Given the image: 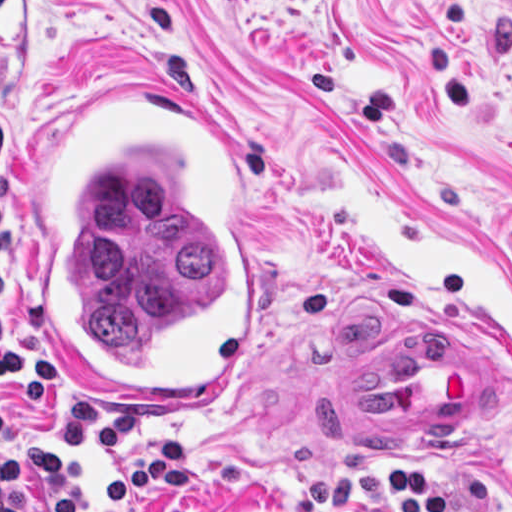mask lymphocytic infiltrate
Wrapping results in <instances>:
<instances>
[{
    "label": "lymphocytic infiltrate",
    "instance_id": "obj_1",
    "mask_svg": "<svg viewBox=\"0 0 512 512\" xmlns=\"http://www.w3.org/2000/svg\"><path fill=\"white\" fill-rule=\"evenodd\" d=\"M17 291V234L0 223V384L16 388L21 411L65 393L62 379L37 347L6 330V311ZM148 429V410L102 412L74 400L65 410L55 449L8 424L0 401V512H123L141 499L168 497L196 472V446L187 433H167L133 452ZM344 473L318 472L293 512H343L354 497L379 496L393 512H491L500 499L512 512V489H497L490 469L473 465L466 503L450 501L416 467L389 471L368 455L344 452Z\"/></svg>",
    "mask_w": 512,
    "mask_h": 512
}]
</instances>
